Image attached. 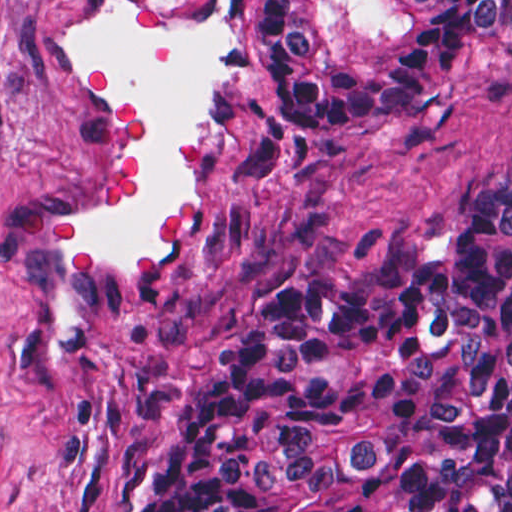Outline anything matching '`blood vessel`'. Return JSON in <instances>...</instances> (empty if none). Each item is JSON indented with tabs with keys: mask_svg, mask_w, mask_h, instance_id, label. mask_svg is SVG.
I'll list each match as a JSON object with an SVG mask.
<instances>
[{
	"mask_svg": "<svg viewBox=\"0 0 512 512\" xmlns=\"http://www.w3.org/2000/svg\"><path fill=\"white\" fill-rule=\"evenodd\" d=\"M257 0H98L46 48L86 126L79 178L35 223L27 365L68 386L105 313L157 294L214 206L239 128Z\"/></svg>",
	"mask_w": 512,
	"mask_h": 512,
	"instance_id": "blood-vessel-1",
	"label": "blood vessel"
}]
</instances>
